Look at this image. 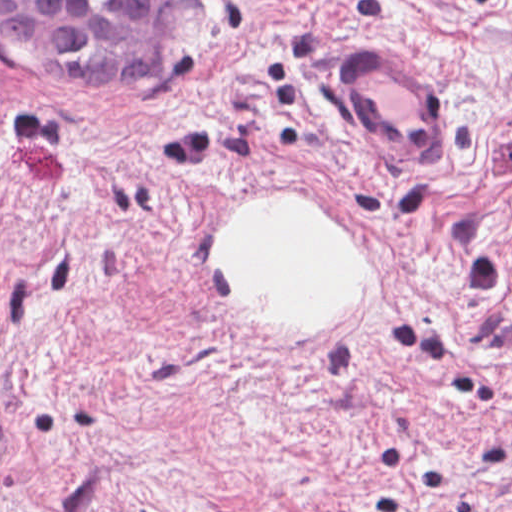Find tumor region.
<instances>
[{"instance_id":"tumor-region-1","label":"tumor region","mask_w":512,"mask_h":512,"mask_svg":"<svg viewBox=\"0 0 512 512\" xmlns=\"http://www.w3.org/2000/svg\"><path fill=\"white\" fill-rule=\"evenodd\" d=\"M171 1H0V49L60 83L155 82Z\"/></svg>"}]
</instances>
